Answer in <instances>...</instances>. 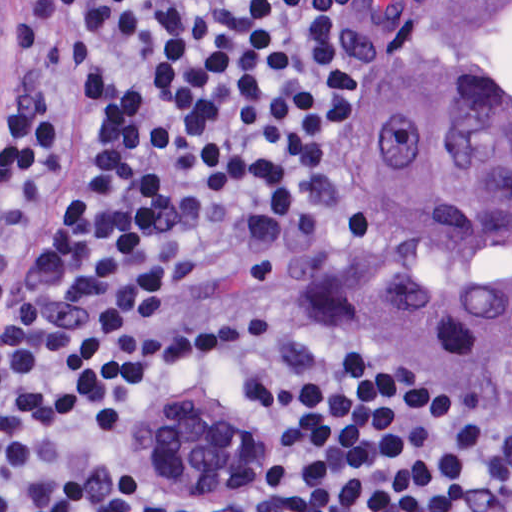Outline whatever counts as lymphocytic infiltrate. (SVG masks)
<instances>
[{
  "label": "lymphocytic infiltrate",
  "mask_w": 512,
  "mask_h": 512,
  "mask_svg": "<svg viewBox=\"0 0 512 512\" xmlns=\"http://www.w3.org/2000/svg\"><path fill=\"white\" fill-rule=\"evenodd\" d=\"M371 0H0V512H512V429L404 381L328 286ZM182 385L267 495L143 479Z\"/></svg>",
  "instance_id": "f902f5d3"
}]
</instances>
